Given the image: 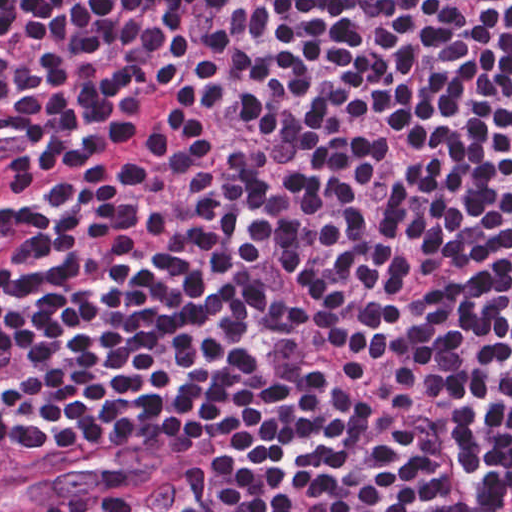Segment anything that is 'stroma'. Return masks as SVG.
I'll return each mask as SVG.
<instances>
[{
  "label": "stroma",
  "instance_id": "35a3bbf8",
  "mask_svg": "<svg viewBox=\"0 0 512 512\" xmlns=\"http://www.w3.org/2000/svg\"><path fill=\"white\" fill-rule=\"evenodd\" d=\"M188 447L189 446L166 447L165 449L168 452V459H166L160 465L143 470L128 472L118 476H103L96 480L95 482L85 486L84 488L70 495L81 493L88 490L124 485L143 479L147 480L152 485L161 490V488L164 486V484L167 482V480L170 478V476L181 463ZM68 496L61 498L47 506H44L32 512H48L54 505L64 500Z\"/></svg>",
  "mask_w": 512,
  "mask_h": 512
}]
</instances>
